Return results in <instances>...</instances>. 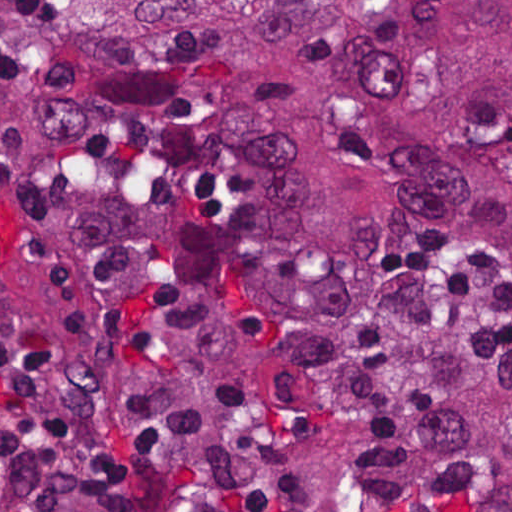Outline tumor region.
<instances>
[{
    "label": "tumor region",
    "instance_id": "1",
    "mask_svg": "<svg viewBox=\"0 0 512 512\" xmlns=\"http://www.w3.org/2000/svg\"><path fill=\"white\" fill-rule=\"evenodd\" d=\"M512 512V0H0V512Z\"/></svg>",
    "mask_w": 512,
    "mask_h": 512
}]
</instances>
